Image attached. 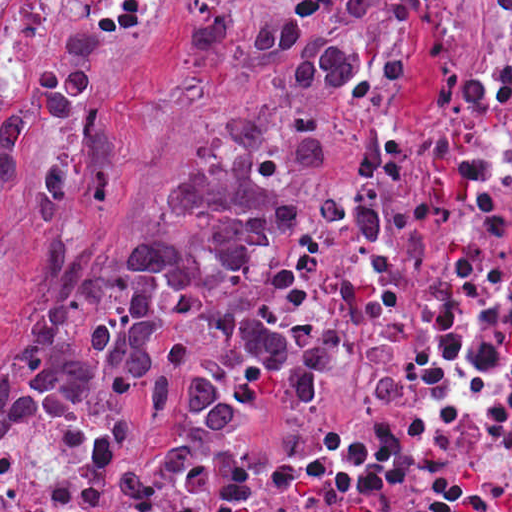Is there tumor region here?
I'll use <instances>...</instances> for the list:
<instances>
[{
	"instance_id": "1",
	"label": "tumor region",
	"mask_w": 512,
	"mask_h": 512,
	"mask_svg": "<svg viewBox=\"0 0 512 512\" xmlns=\"http://www.w3.org/2000/svg\"><path fill=\"white\" fill-rule=\"evenodd\" d=\"M39 388H109L135 414L225 433L253 401L316 393L318 356L236 310L222 272L1 371L0 417Z\"/></svg>"
}]
</instances>
